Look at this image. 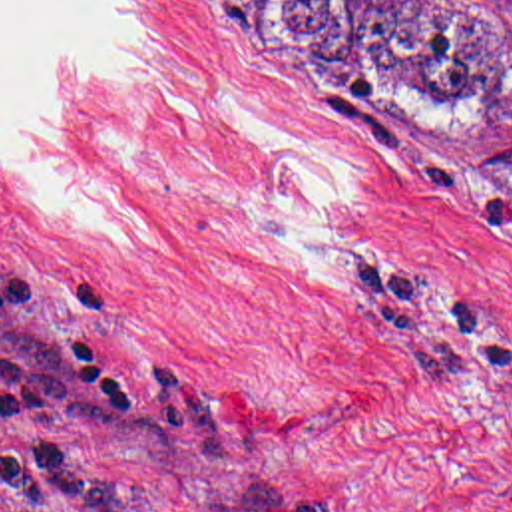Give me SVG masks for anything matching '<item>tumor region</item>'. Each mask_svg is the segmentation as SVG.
<instances>
[{"mask_svg":"<svg viewBox=\"0 0 512 512\" xmlns=\"http://www.w3.org/2000/svg\"><path fill=\"white\" fill-rule=\"evenodd\" d=\"M228 1L278 57L353 99L465 117L512 97V0ZM461 173L512 189V139Z\"/></svg>","mask_w":512,"mask_h":512,"instance_id":"tumor-region-1","label":"tumor region"}]
</instances>
